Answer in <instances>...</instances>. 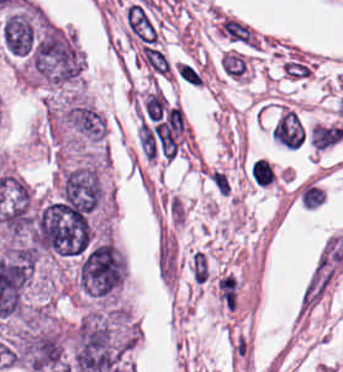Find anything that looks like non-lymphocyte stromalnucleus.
Listing matches in <instances>:
<instances>
[{
	"label": "non-lymphocyte stromal nucleus",
	"instance_id": "non-lymphocyte-stromal-nucleus-2",
	"mask_svg": "<svg viewBox=\"0 0 343 372\" xmlns=\"http://www.w3.org/2000/svg\"><path fill=\"white\" fill-rule=\"evenodd\" d=\"M271 136L281 145L296 149L303 137V128L297 115L285 111L271 129Z\"/></svg>",
	"mask_w": 343,
	"mask_h": 372
},
{
	"label": "non-lymphocyte stromal nucleus",
	"instance_id": "non-lymphocyte-stromal-nucleus-1",
	"mask_svg": "<svg viewBox=\"0 0 343 372\" xmlns=\"http://www.w3.org/2000/svg\"><path fill=\"white\" fill-rule=\"evenodd\" d=\"M123 20L138 44L158 51V30L145 2L128 5L123 10Z\"/></svg>",
	"mask_w": 343,
	"mask_h": 372
},
{
	"label": "non-lymphocyte stromal nucleus",
	"instance_id": "non-lymphocyte-stromal-nucleus-5",
	"mask_svg": "<svg viewBox=\"0 0 343 372\" xmlns=\"http://www.w3.org/2000/svg\"><path fill=\"white\" fill-rule=\"evenodd\" d=\"M175 76L189 86H196L201 81V75L196 68L186 62L174 66Z\"/></svg>",
	"mask_w": 343,
	"mask_h": 372
},
{
	"label": "non-lymphocyte stromal nucleus",
	"instance_id": "non-lymphocyte-stromal-nucleus-4",
	"mask_svg": "<svg viewBox=\"0 0 343 372\" xmlns=\"http://www.w3.org/2000/svg\"><path fill=\"white\" fill-rule=\"evenodd\" d=\"M244 57L233 51L223 52L220 59V71L230 78H242L244 74Z\"/></svg>",
	"mask_w": 343,
	"mask_h": 372
},
{
	"label": "non-lymphocyte stromal nucleus",
	"instance_id": "non-lymphocyte-stromal-nucleus-6",
	"mask_svg": "<svg viewBox=\"0 0 343 372\" xmlns=\"http://www.w3.org/2000/svg\"><path fill=\"white\" fill-rule=\"evenodd\" d=\"M191 272L200 283L207 278L205 255L201 251H194L191 255Z\"/></svg>",
	"mask_w": 343,
	"mask_h": 372
},
{
	"label": "non-lymphocyte stromal nucleus",
	"instance_id": "non-lymphocyte-stromal-nucleus-3",
	"mask_svg": "<svg viewBox=\"0 0 343 372\" xmlns=\"http://www.w3.org/2000/svg\"><path fill=\"white\" fill-rule=\"evenodd\" d=\"M310 138L312 147L322 151L343 139V126L313 124Z\"/></svg>",
	"mask_w": 343,
	"mask_h": 372
}]
</instances>
